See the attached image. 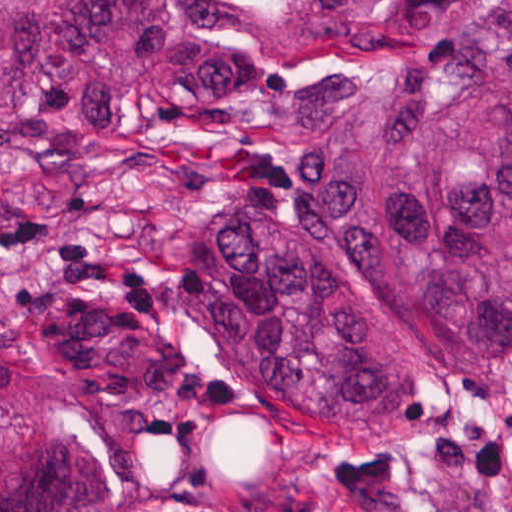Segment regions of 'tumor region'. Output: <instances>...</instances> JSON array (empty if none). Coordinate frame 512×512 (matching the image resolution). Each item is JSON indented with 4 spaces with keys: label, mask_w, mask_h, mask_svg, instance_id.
I'll return each instance as SVG.
<instances>
[{
    "label": "tumor region",
    "mask_w": 512,
    "mask_h": 512,
    "mask_svg": "<svg viewBox=\"0 0 512 512\" xmlns=\"http://www.w3.org/2000/svg\"><path fill=\"white\" fill-rule=\"evenodd\" d=\"M234 0H0V154L93 162L157 95L287 135L286 202L178 220L167 285L200 348L357 450L422 435L452 378L512 365V0H272L267 81ZM0 512H104L82 422L0 423Z\"/></svg>",
    "instance_id": "tumor-region-1"
}]
</instances>
